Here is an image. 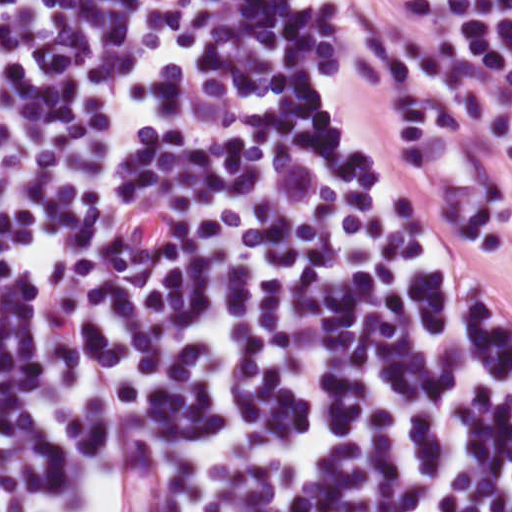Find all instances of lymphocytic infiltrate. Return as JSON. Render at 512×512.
Wrapping results in <instances>:
<instances>
[{"label": "lymphocytic infiltrate", "instance_id": "obj_1", "mask_svg": "<svg viewBox=\"0 0 512 512\" xmlns=\"http://www.w3.org/2000/svg\"><path fill=\"white\" fill-rule=\"evenodd\" d=\"M155 473L0 123V512H174L119 507Z\"/></svg>", "mask_w": 512, "mask_h": 512}]
</instances>
